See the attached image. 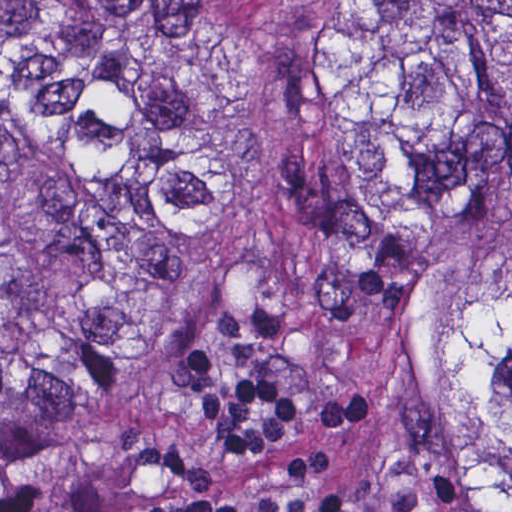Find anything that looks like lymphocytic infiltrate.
Wrapping results in <instances>:
<instances>
[{"instance_id":"1","label":"lymphocytic infiltrate","mask_w":512,"mask_h":512,"mask_svg":"<svg viewBox=\"0 0 512 512\" xmlns=\"http://www.w3.org/2000/svg\"><path fill=\"white\" fill-rule=\"evenodd\" d=\"M218 327L241 368L221 373L196 337L175 351L170 374L199 400L205 438L217 456L248 464L280 444L303 421V398L269 376L267 360L283 345L288 321L267 305H246L219 318ZM375 409L368 389L339 393L320 402L318 445L289 465L288 493L255 497L165 498L146 512H343L336 493H310L312 479L326 466V444L332 432L361 424ZM120 451L90 481L82 484H38L0 499V512H110L111 487L143 466H155L193 485L213 484L212 471L188 456L173 441L153 439L130 430L117 436Z\"/></svg>"}]
</instances>
